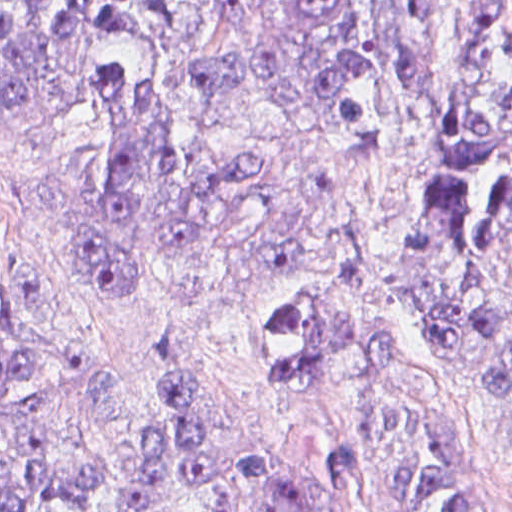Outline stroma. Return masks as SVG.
<instances>
[{
	"label": "stroma",
	"instance_id": "stroma-1",
	"mask_svg": "<svg viewBox=\"0 0 512 512\" xmlns=\"http://www.w3.org/2000/svg\"><path fill=\"white\" fill-rule=\"evenodd\" d=\"M495 1L440 0L427 92L409 110L379 117L347 140L225 108L200 116L194 132L201 145L280 156L304 177L308 205L270 231L263 250L270 264L172 260L121 280L89 282L70 222L86 133L63 129L0 142V339L118 360L164 333L179 338L217 417L275 452L308 512H380L334 488L319 398L286 387L245 353L243 333L253 314L284 304L320 317L395 320L432 354L450 454L488 512H512V420L463 362L390 304L294 271L332 265L386 278L404 265L434 144L465 78L471 27Z\"/></svg>",
	"mask_w": 512,
	"mask_h": 512
}]
</instances>
